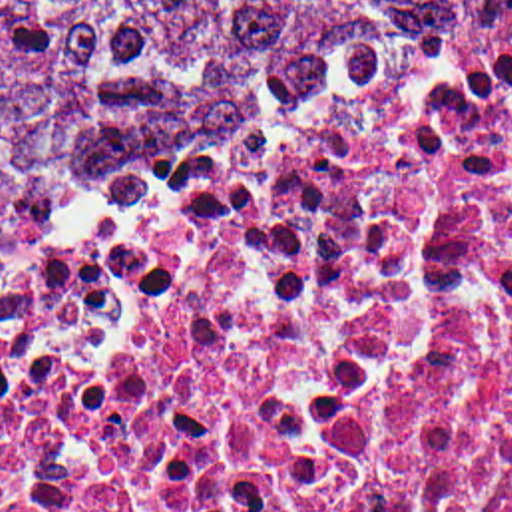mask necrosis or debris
Wrapping results in <instances>:
<instances>
[{"label": "necrosis or debris", "instance_id": "necrosis-or-debris-1", "mask_svg": "<svg viewBox=\"0 0 512 512\" xmlns=\"http://www.w3.org/2000/svg\"><path fill=\"white\" fill-rule=\"evenodd\" d=\"M0 512H512V0L2 271Z\"/></svg>", "mask_w": 512, "mask_h": 512}]
</instances>
